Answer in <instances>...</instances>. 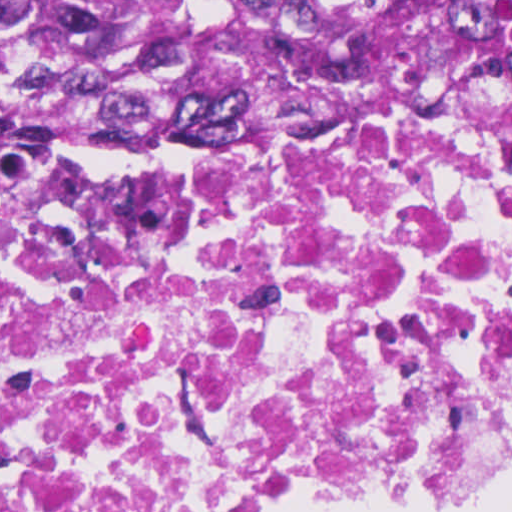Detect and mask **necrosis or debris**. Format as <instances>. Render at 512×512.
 Segmentation results:
<instances>
[{"label":"necrosis or debris","mask_w":512,"mask_h":512,"mask_svg":"<svg viewBox=\"0 0 512 512\" xmlns=\"http://www.w3.org/2000/svg\"><path fill=\"white\" fill-rule=\"evenodd\" d=\"M512 460V89L0 149V512H325Z\"/></svg>","instance_id":"necrosis-or-debris-1"}]
</instances>
